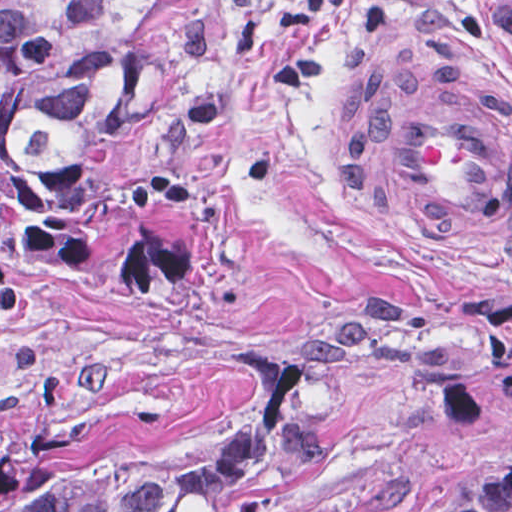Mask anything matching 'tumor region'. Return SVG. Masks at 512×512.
<instances>
[{
    "mask_svg": "<svg viewBox=\"0 0 512 512\" xmlns=\"http://www.w3.org/2000/svg\"><path fill=\"white\" fill-rule=\"evenodd\" d=\"M212 2L1 0V169L56 165L124 132L165 91ZM278 366L219 444L124 472H31L1 489L0 512H248L319 458L377 380H426L339 344Z\"/></svg>",
    "mask_w": 512,
    "mask_h": 512,
    "instance_id": "1",
    "label": "tumor region"
}]
</instances>
